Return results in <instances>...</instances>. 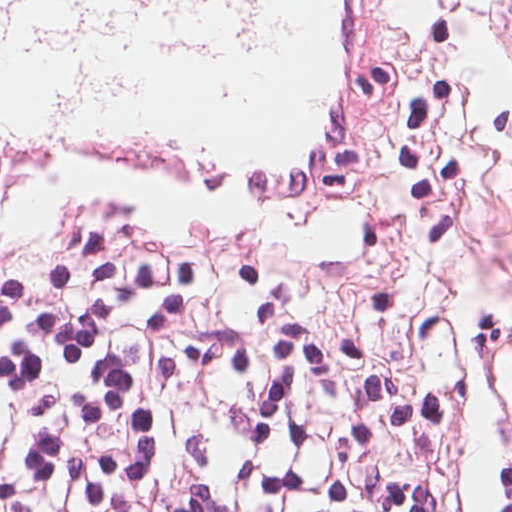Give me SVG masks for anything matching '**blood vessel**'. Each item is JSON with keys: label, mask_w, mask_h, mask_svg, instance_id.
<instances>
[{"label": "blood vessel", "mask_w": 512, "mask_h": 512, "mask_svg": "<svg viewBox=\"0 0 512 512\" xmlns=\"http://www.w3.org/2000/svg\"><path fill=\"white\" fill-rule=\"evenodd\" d=\"M392 148L378 0H269L229 61L133 78L94 114L62 111L27 55L0 57V210L49 176L131 171L251 208L357 197Z\"/></svg>", "instance_id": "8fb6f2fc"}]
</instances>
